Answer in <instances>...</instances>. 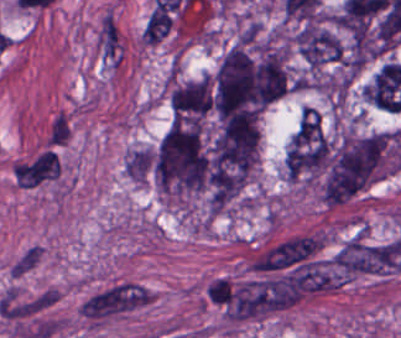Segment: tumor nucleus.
<instances>
[{"label": "tumor nucleus", "mask_w": 401, "mask_h": 338, "mask_svg": "<svg viewBox=\"0 0 401 338\" xmlns=\"http://www.w3.org/2000/svg\"><path fill=\"white\" fill-rule=\"evenodd\" d=\"M212 98L211 75L176 80L169 88L171 120H202L211 114Z\"/></svg>", "instance_id": "2cbd58db"}, {"label": "tumor nucleus", "mask_w": 401, "mask_h": 338, "mask_svg": "<svg viewBox=\"0 0 401 338\" xmlns=\"http://www.w3.org/2000/svg\"><path fill=\"white\" fill-rule=\"evenodd\" d=\"M293 41L303 62L313 70L340 60L344 55L343 44L320 17L299 22Z\"/></svg>", "instance_id": "5ab6c2c4"}, {"label": "tumor nucleus", "mask_w": 401, "mask_h": 338, "mask_svg": "<svg viewBox=\"0 0 401 338\" xmlns=\"http://www.w3.org/2000/svg\"><path fill=\"white\" fill-rule=\"evenodd\" d=\"M401 166L392 131L348 133L326 139L318 181L324 202H344Z\"/></svg>", "instance_id": "2f306a5c"}, {"label": "tumor nucleus", "mask_w": 401, "mask_h": 338, "mask_svg": "<svg viewBox=\"0 0 401 338\" xmlns=\"http://www.w3.org/2000/svg\"><path fill=\"white\" fill-rule=\"evenodd\" d=\"M152 175L163 191L186 196L206 185L207 150L200 118L171 124L154 150Z\"/></svg>", "instance_id": "8643909e"}]
</instances>
